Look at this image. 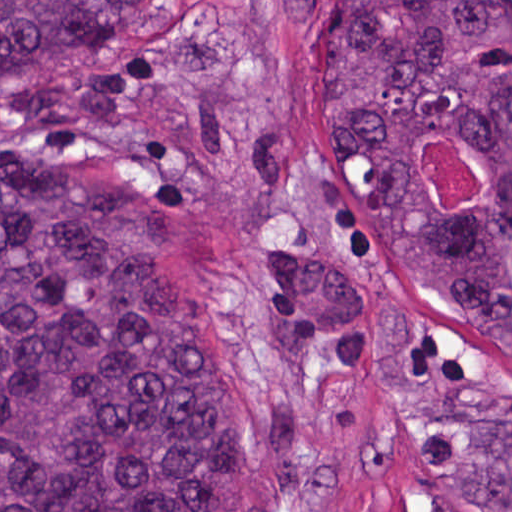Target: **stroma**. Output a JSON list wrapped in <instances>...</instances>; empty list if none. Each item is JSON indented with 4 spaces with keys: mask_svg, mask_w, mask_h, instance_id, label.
<instances>
[{
    "mask_svg": "<svg viewBox=\"0 0 512 512\" xmlns=\"http://www.w3.org/2000/svg\"><path fill=\"white\" fill-rule=\"evenodd\" d=\"M344 0H185L0 80V166L79 163L164 199L167 231L228 322L267 415L281 389L265 257L331 234L377 249L416 309L465 349L512 368L462 313L426 290L318 119L323 45ZM422 160L442 202H475L474 155L440 129ZM359 368L316 352L305 427L320 446L372 443L373 478L269 512H482L364 316Z\"/></svg>",
    "mask_w": 512,
    "mask_h": 512,
    "instance_id": "1",
    "label": "stroma"
}]
</instances>
